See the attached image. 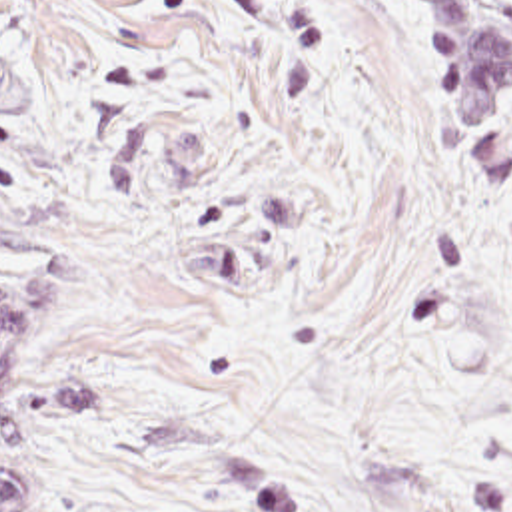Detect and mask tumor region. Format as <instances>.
<instances>
[{
  "instance_id": "obj_1",
  "label": "tumor region",
  "mask_w": 512,
  "mask_h": 512,
  "mask_svg": "<svg viewBox=\"0 0 512 512\" xmlns=\"http://www.w3.org/2000/svg\"><path fill=\"white\" fill-rule=\"evenodd\" d=\"M431 55L439 107L461 131H471L459 0L443 1L431 31ZM12 394L20 398L18 343L12 309L0 283V410ZM226 478L234 512H306L296 490L246 448L228 450ZM32 490L34 470L0 474V512H22Z\"/></svg>"
}]
</instances>
